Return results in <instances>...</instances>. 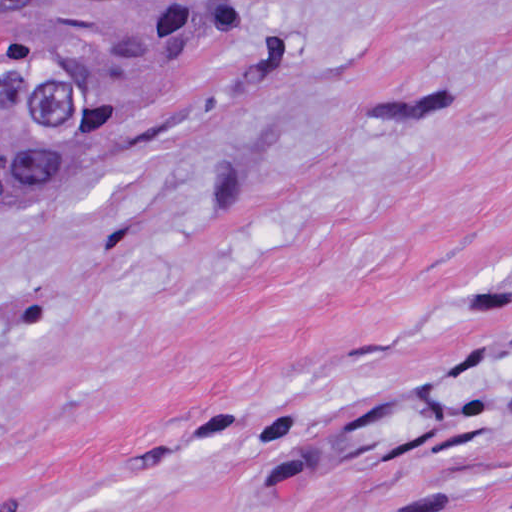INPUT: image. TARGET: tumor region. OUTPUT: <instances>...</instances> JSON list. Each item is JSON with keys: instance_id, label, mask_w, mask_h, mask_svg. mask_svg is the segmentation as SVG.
Segmentation results:
<instances>
[{"instance_id": "tumor-region-1", "label": "tumor region", "mask_w": 512, "mask_h": 512, "mask_svg": "<svg viewBox=\"0 0 512 512\" xmlns=\"http://www.w3.org/2000/svg\"><path fill=\"white\" fill-rule=\"evenodd\" d=\"M239 0H0V201L122 94L220 45Z\"/></svg>"}]
</instances>
